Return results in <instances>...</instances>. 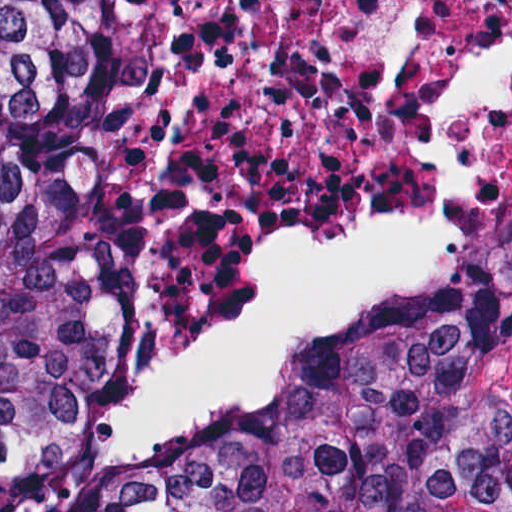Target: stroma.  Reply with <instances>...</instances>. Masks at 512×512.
<instances>
[{
    "instance_id": "1",
    "label": "stroma",
    "mask_w": 512,
    "mask_h": 512,
    "mask_svg": "<svg viewBox=\"0 0 512 512\" xmlns=\"http://www.w3.org/2000/svg\"><path fill=\"white\" fill-rule=\"evenodd\" d=\"M109 242L107 213L91 182L73 291V412L94 463V413L103 349V264ZM482 263H508L504 254ZM502 401L512 430V313L502 334Z\"/></svg>"
}]
</instances>
